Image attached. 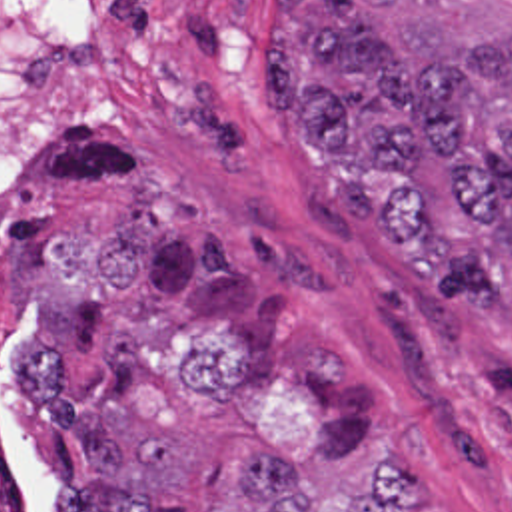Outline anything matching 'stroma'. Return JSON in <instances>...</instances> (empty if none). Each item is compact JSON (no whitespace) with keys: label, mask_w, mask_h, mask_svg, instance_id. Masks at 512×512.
<instances>
[{"label":"stroma","mask_w":512,"mask_h":512,"mask_svg":"<svg viewBox=\"0 0 512 512\" xmlns=\"http://www.w3.org/2000/svg\"><path fill=\"white\" fill-rule=\"evenodd\" d=\"M276 0H96L68 146L30 222L98 238L156 196L190 224L214 298L322 329L360 359L376 421L430 449L444 512H512V304H450L384 236L398 182L330 168L262 94ZM50 499L56 461L14 419Z\"/></svg>","instance_id":"1"}]
</instances>
